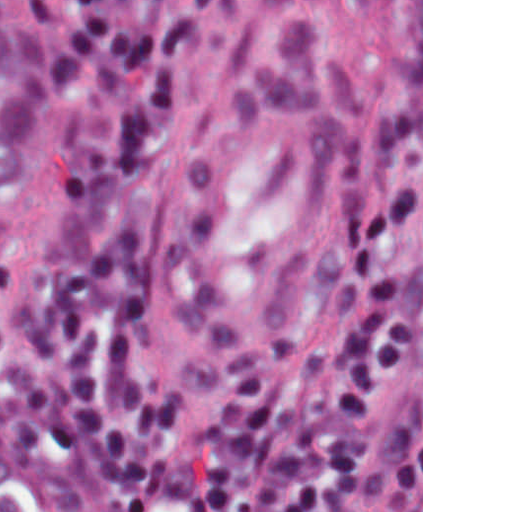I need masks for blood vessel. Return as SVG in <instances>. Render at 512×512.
Returning <instances> with one entry per match:
<instances>
[{
	"label": "blood vessel",
	"instance_id": "blood-vessel-1",
	"mask_svg": "<svg viewBox=\"0 0 512 512\" xmlns=\"http://www.w3.org/2000/svg\"><path fill=\"white\" fill-rule=\"evenodd\" d=\"M393 57L387 1L255 2L179 239L180 310L208 341L268 336L311 281Z\"/></svg>",
	"mask_w": 512,
	"mask_h": 512
}]
</instances>
